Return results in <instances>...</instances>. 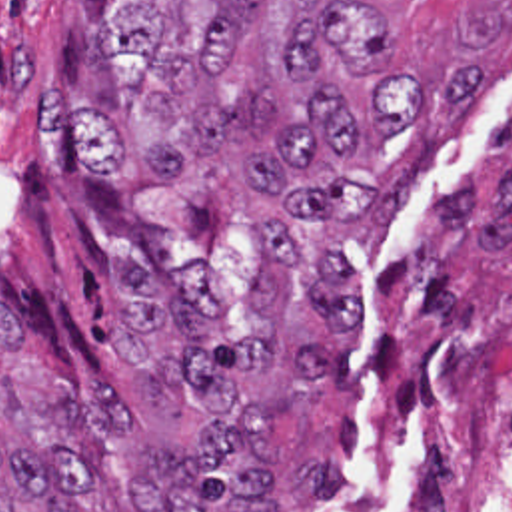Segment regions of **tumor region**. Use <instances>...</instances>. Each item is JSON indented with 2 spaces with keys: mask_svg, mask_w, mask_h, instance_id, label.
<instances>
[{
  "mask_svg": "<svg viewBox=\"0 0 512 512\" xmlns=\"http://www.w3.org/2000/svg\"><path fill=\"white\" fill-rule=\"evenodd\" d=\"M131 1L95 39L119 107L49 89L45 127L67 129L91 175L209 161L259 191L253 310L271 328H231L203 269L151 279L123 261L119 370L175 380L203 414L201 442L157 444L119 382L45 364L0 308V512H281L267 418L321 396L359 314L367 279L343 241H379L479 71L467 51L423 73L365 1Z\"/></svg>",
  "mask_w": 512,
  "mask_h": 512,
  "instance_id": "obj_1",
  "label": "tumor region"
}]
</instances>
